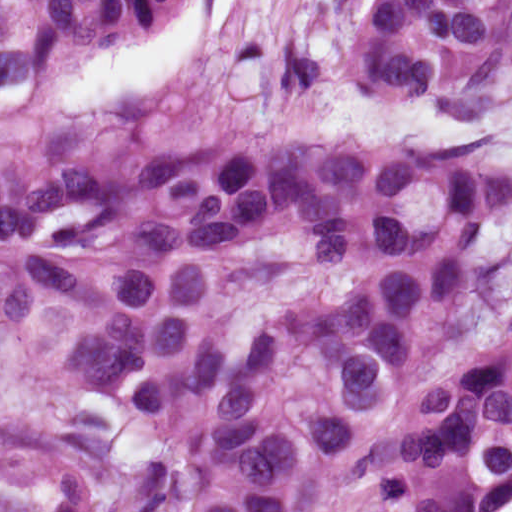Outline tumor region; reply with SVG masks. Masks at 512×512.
I'll list each match as a JSON object with an SVG mask.
<instances>
[{"mask_svg":"<svg viewBox=\"0 0 512 512\" xmlns=\"http://www.w3.org/2000/svg\"><path fill=\"white\" fill-rule=\"evenodd\" d=\"M168 0H0V512L512 504V0H369L370 75L475 135L80 152L68 58Z\"/></svg>","mask_w":512,"mask_h":512,"instance_id":"obj_1","label":"tumor region"}]
</instances>
